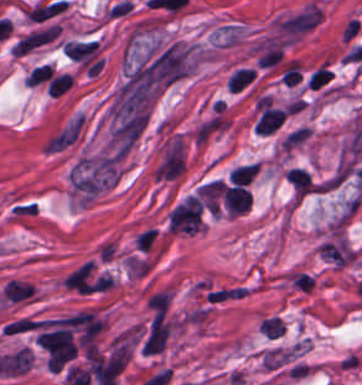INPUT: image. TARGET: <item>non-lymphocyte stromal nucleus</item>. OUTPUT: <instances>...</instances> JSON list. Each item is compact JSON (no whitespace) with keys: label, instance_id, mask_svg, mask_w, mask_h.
Wrapping results in <instances>:
<instances>
[{"label":"non-lymphocyte stromal nucleus","instance_id":"obj_1","mask_svg":"<svg viewBox=\"0 0 362 385\" xmlns=\"http://www.w3.org/2000/svg\"><path fill=\"white\" fill-rule=\"evenodd\" d=\"M322 22V9L309 0L275 20L277 34L285 39H301Z\"/></svg>","mask_w":362,"mask_h":385},{"label":"non-lymphocyte stromal nucleus","instance_id":"obj_2","mask_svg":"<svg viewBox=\"0 0 362 385\" xmlns=\"http://www.w3.org/2000/svg\"><path fill=\"white\" fill-rule=\"evenodd\" d=\"M84 115L76 112L46 139L48 154H58L76 142L82 134Z\"/></svg>","mask_w":362,"mask_h":385}]
</instances>
